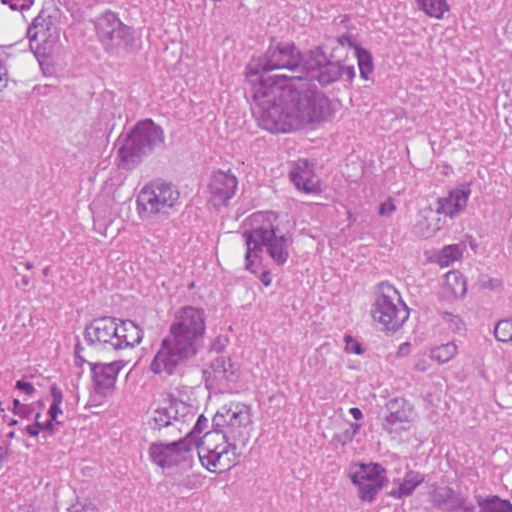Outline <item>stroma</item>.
<instances>
[{
	"mask_svg": "<svg viewBox=\"0 0 512 512\" xmlns=\"http://www.w3.org/2000/svg\"><path fill=\"white\" fill-rule=\"evenodd\" d=\"M107 1L167 19L203 0ZM79 7L29 16L23 48L35 103L0 114V371L73 324L94 292L78 214L94 188H110L108 126L140 99V78L88 39ZM414 16L403 0L236 1L188 31L176 115L203 149L242 165L254 204L275 200L305 158L333 161V188L329 205L286 209L278 249L251 282L227 281L203 257L202 208L183 201L173 221L150 225L151 269L166 291L225 292L252 337L270 373V435L202 499L115 488V512H364L312 449L304 404L324 389L367 385L348 322L387 270L431 274L419 216L442 177L388 96L369 87L328 136L263 145L238 120L234 55L273 26L339 23L382 39Z\"/></svg>",
	"mask_w": 512,
	"mask_h": 512,
	"instance_id": "obj_1",
	"label": "stroma"
}]
</instances>
